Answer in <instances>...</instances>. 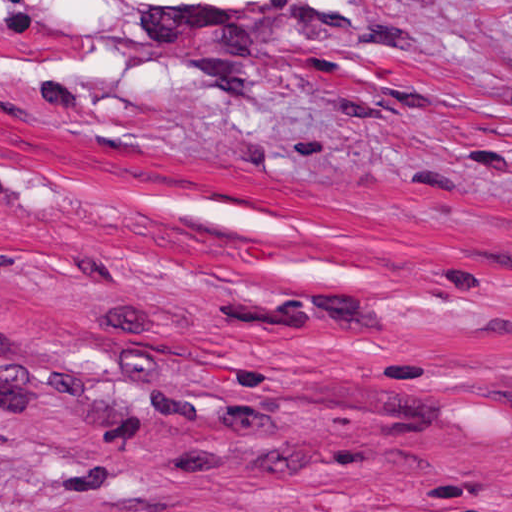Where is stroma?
Here are the masks:
<instances>
[{
  "mask_svg": "<svg viewBox=\"0 0 512 512\" xmlns=\"http://www.w3.org/2000/svg\"><path fill=\"white\" fill-rule=\"evenodd\" d=\"M0 512H512V0H0Z\"/></svg>",
  "mask_w": 512,
  "mask_h": 512,
  "instance_id": "1",
  "label": "stroma"
}]
</instances>
